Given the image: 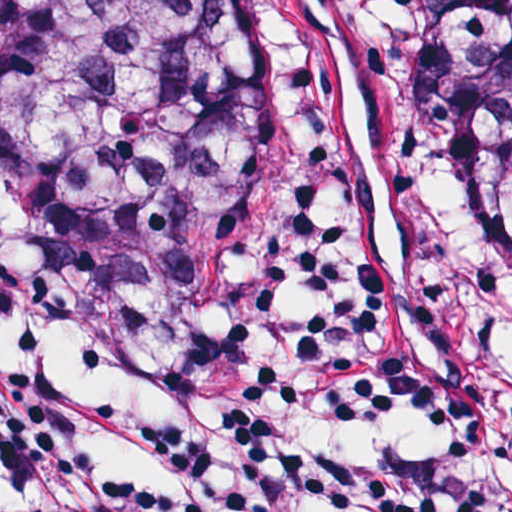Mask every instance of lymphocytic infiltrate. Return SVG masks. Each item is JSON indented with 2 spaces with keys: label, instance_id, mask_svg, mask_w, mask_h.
<instances>
[{
  "label": "lymphocytic infiltrate",
  "instance_id": "obj_1",
  "mask_svg": "<svg viewBox=\"0 0 512 512\" xmlns=\"http://www.w3.org/2000/svg\"><path fill=\"white\" fill-rule=\"evenodd\" d=\"M0 298L171 403L144 435L179 482L161 487L116 467L77 406L0 346V472L27 512H512V336L453 251L367 196L282 204L243 292L180 305L104 287L0 209ZM388 409L422 413L435 449L288 452L303 423Z\"/></svg>",
  "mask_w": 512,
  "mask_h": 512
}]
</instances>
